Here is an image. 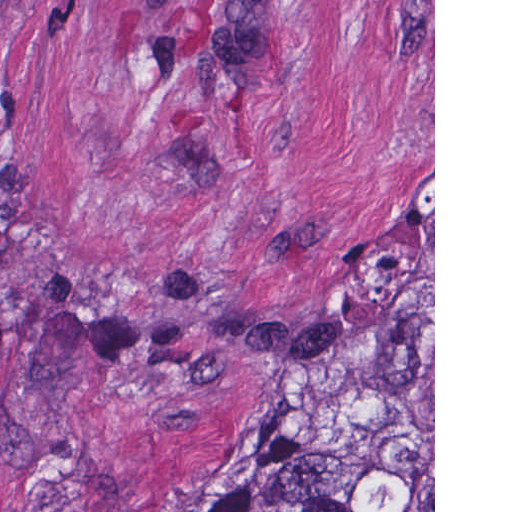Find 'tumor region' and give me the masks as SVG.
Masks as SVG:
<instances>
[{"label": "tumor region", "mask_w": 512, "mask_h": 512, "mask_svg": "<svg viewBox=\"0 0 512 512\" xmlns=\"http://www.w3.org/2000/svg\"><path fill=\"white\" fill-rule=\"evenodd\" d=\"M210 512H433V305L347 332L274 422V473Z\"/></svg>", "instance_id": "1"}]
</instances>
